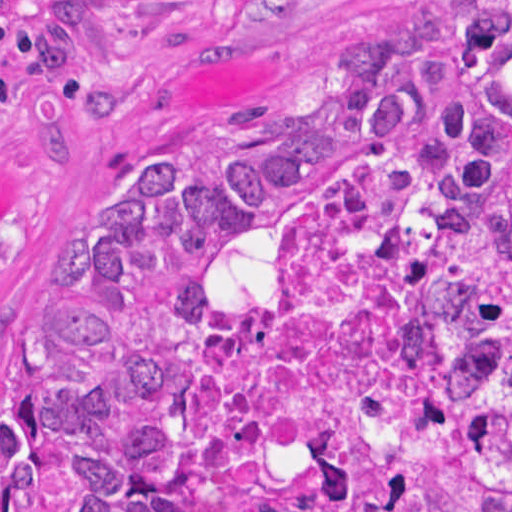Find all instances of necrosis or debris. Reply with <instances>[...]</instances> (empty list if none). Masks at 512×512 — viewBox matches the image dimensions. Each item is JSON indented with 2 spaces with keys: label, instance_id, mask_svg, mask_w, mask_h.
I'll return each mask as SVG.
<instances>
[{
  "label": "necrosis or debris",
  "instance_id": "4bbe7bcc",
  "mask_svg": "<svg viewBox=\"0 0 512 512\" xmlns=\"http://www.w3.org/2000/svg\"><path fill=\"white\" fill-rule=\"evenodd\" d=\"M448 237L440 187L413 155L382 148L326 182L263 297L198 352L179 512L310 510L334 456L361 503L413 499L400 470L453 412Z\"/></svg>",
  "mask_w": 512,
  "mask_h": 512
}]
</instances>
